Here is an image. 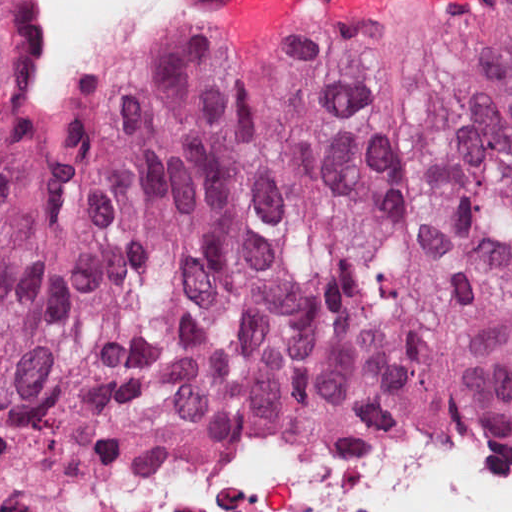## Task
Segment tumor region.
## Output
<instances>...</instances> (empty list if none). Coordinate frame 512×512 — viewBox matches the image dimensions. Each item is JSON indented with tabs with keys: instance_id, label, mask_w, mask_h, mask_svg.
<instances>
[{
	"instance_id": "obj_1",
	"label": "tumor region",
	"mask_w": 512,
	"mask_h": 512,
	"mask_svg": "<svg viewBox=\"0 0 512 512\" xmlns=\"http://www.w3.org/2000/svg\"><path fill=\"white\" fill-rule=\"evenodd\" d=\"M238 413L512 442V0L172 30L0 151V425L58 473Z\"/></svg>"
}]
</instances>
